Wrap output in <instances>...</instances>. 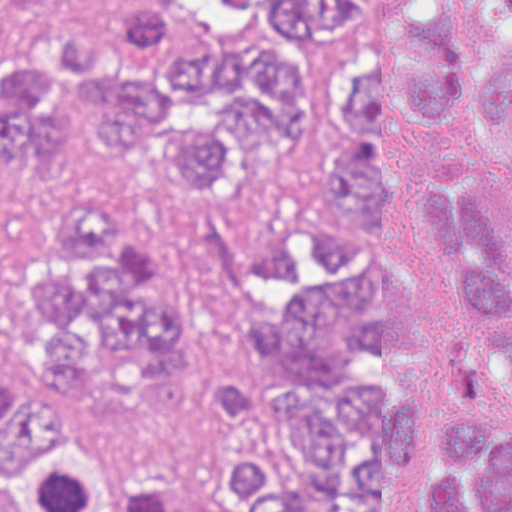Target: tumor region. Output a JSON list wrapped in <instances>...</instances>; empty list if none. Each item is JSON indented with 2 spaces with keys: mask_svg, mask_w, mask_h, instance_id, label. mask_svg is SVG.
<instances>
[{
  "mask_svg": "<svg viewBox=\"0 0 512 512\" xmlns=\"http://www.w3.org/2000/svg\"><path fill=\"white\" fill-rule=\"evenodd\" d=\"M481 1L483 65L450 0H271L227 46L176 1L124 0L111 27L0 43V176L22 185L0 512H512V221L461 165L395 170L400 126L481 104L512 162V0ZM67 122L213 199L246 160L319 155L349 220L439 272L296 207L260 238L238 389L207 397L191 305L83 182Z\"/></svg>",
  "mask_w": 512,
  "mask_h": 512,
  "instance_id": "obj_1",
  "label": "tumor region"
}]
</instances>
